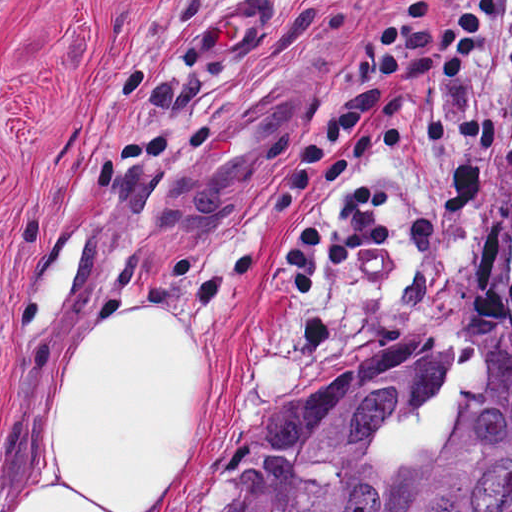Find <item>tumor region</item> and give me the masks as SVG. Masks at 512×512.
<instances>
[{
    "mask_svg": "<svg viewBox=\"0 0 512 512\" xmlns=\"http://www.w3.org/2000/svg\"><path fill=\"white\" fill-rule=\"evenodd\" d=\"M454 351L437 334L380 343L263 418L227 512H512V362L466 398L449 443L392 464V419Z\"/></svg>",
    "mask_w": 512,
    "mask_h": 512,
    "instance_id": "obj_1",
    "label": "tumor region"
}]
</instances>
